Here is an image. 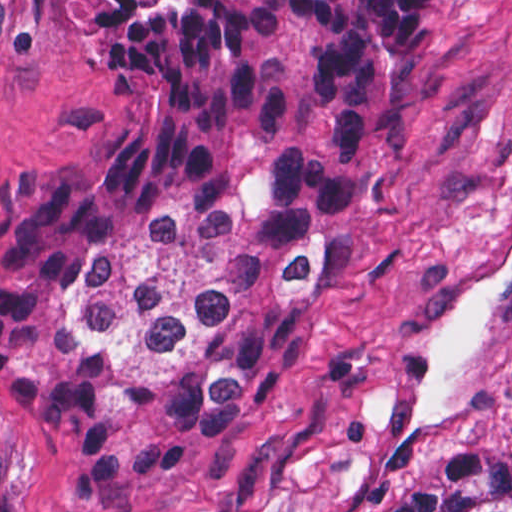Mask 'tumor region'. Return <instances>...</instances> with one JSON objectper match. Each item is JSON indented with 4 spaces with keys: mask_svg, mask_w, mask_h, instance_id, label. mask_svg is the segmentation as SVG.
<instances>
[{
    "mask_svg": "<svg viewBox=\"0 0 512 512\" xmlns=\"http://www.w3.org/2000/svg\"><path fill=\"white\" fill-rule=\"evenodd\" d=\"M75 1L123 126L0 193V385L125 510L224 451L346 271L429 97L425 0ZM367 512H512V455L436 443Z\"/></svg>",
    "mask_w": 512,
    "mask_h": 512,
    "instance_id": "1",
    "label": "tumor region"
}]
</instances>
